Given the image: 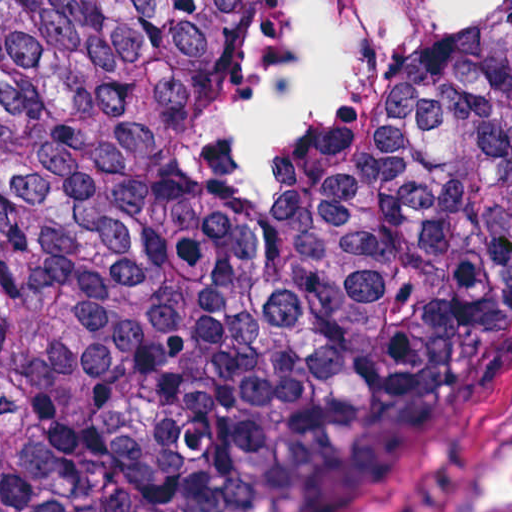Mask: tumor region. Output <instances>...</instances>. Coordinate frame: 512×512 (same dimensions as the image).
Instances as JSON below:
<instances>
[{"mask_svg":"<svg viewBox=\"0 0 512 512\" xmlns=\"http://www.w3.org/2000/svg\"><path fill=\"white\" fill-rule=\"evenodd\" d=\"M241 1L0 0V512H379L512 351V7L209 167Z\"/></svg>","mask_w":512,"mask_h":512,"instance_id":"1","label":"tumor region"}]
</instances>
